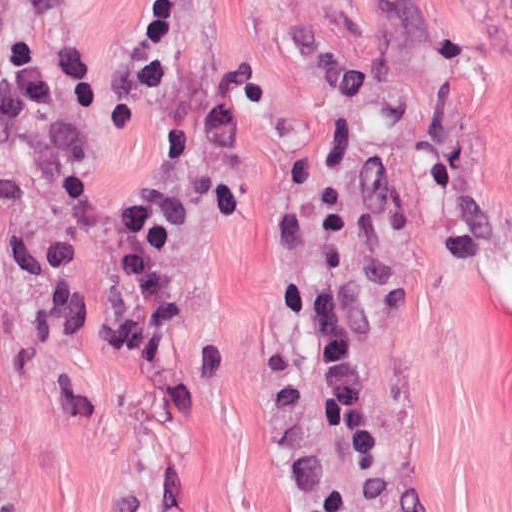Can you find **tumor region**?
<instances>
[{
	"label": "tumor region",
	"instance_id": "1",
	"mask_svg": "<svg viewBox=\"0 0 512 512\" xmlns=\"http://www.w3.org/2000/svg\"><path fill=\"white\" fill-rule=\"evenodd\" d=\"M267 496L277 500V512H308L283 501L278 500V486Z\"/></svg>",
	"mask_w": 512,
	"mask_h": 512
}]
</instances>
